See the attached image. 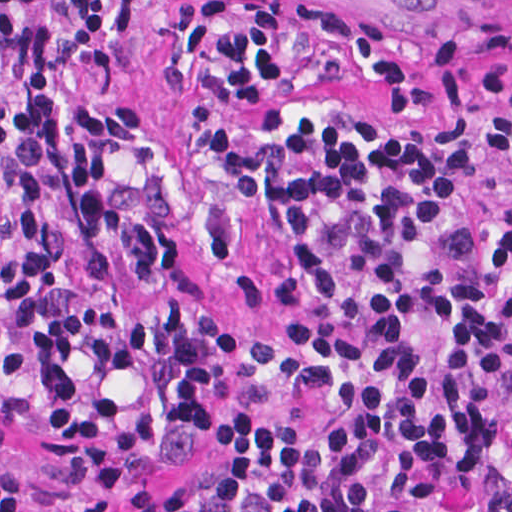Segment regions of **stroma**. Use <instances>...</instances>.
I'll use <instances>...</instances> for the list:
<instances>
[{"label":"stroma","mask_w":512,"mask_h":512,"mask_svg":"<svg viewBox=\"0 0 512 512\" xmlns=\"http://www.w3.org/2000/svg\"><path fill=\"white\" fill-rule=\"evenodd\" d=\"M145 0L138 33L118 73L93 76L81 53L104 43L114 0H104L91 37L64 81L72 105L144 114L137 139L103 149L116 198L149 212L172 237V262L156 282L135 270L107 240L104 276L87 284L79 233L67 192L56 187L61 256L77 289L113 304L137 359L133 369L104 374L73 358L77 391L96 404L119 406L152 436L150 466L139 475L92 474L57 452L53 403L39 371L11 327V273L22 255L20 217L3 188L0 162V420L13 449L1 472L28 477L26 512H269L261 487L234 485L229 459L207 440L219 418L257 417L288 431L325 428L335 405L327 397L285 399V386L260 384L249 347L286 343L283 289L296 241L265 204L240 196L212 158L214 131L273 140L296 120L321 118L347 136H396L455 158L453 196L440 218L417 227L409 250L421 281L453 286L472 272L503 309L512 307V155H492L486 134L495 99L468 110L438 105L416 119L385 112L383 99L356 67L332 78L310 67L274 110H231L195 123L202 68L190 86L169 90L165 56L175 45L178 4ZM351 6L379 18L397 53L414 40L451 28L469 43L476 66L493 32L510 37V0H308ZM0 89L13 130L17 107L0 58Z\"/></svg>","instance_id":"35a3bbf8"}]
</instances>
